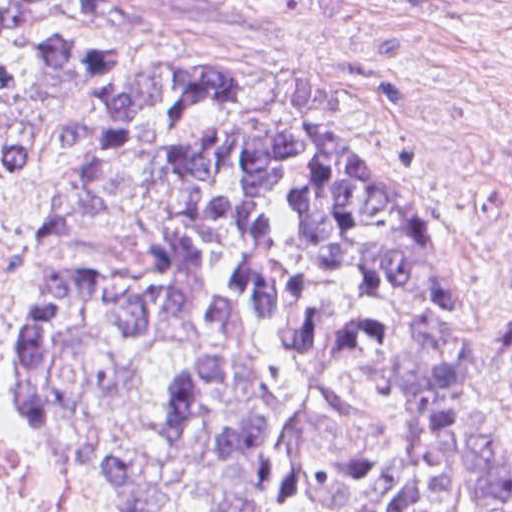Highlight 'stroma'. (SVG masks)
I'll use <instances>...</instances> for the list:
<instances>
[{
  "mask_svg": "<svg viewBox=\"0 0 512 512\" xmlns=\"http://www.w3.org/2000/svg\"><path fill=\"white\" fill-rule=\"evenodd\" d=\"M0 1H35L39 24L99 49L216 68L263 111L356 142L376 183L434 222L461 295V493L483 471L502 386L512 459V0ZM73 101L45 102L31 157L0 167V210L27 231L66 177L59 129ZM31 292L0 264V512H132L76 485L24 427Z\"/></svg>",
  "mask_w": 512,
  "mask_h": 512,
  "instance_id": "1",
  "label": "stroma"
}]
</instances>
